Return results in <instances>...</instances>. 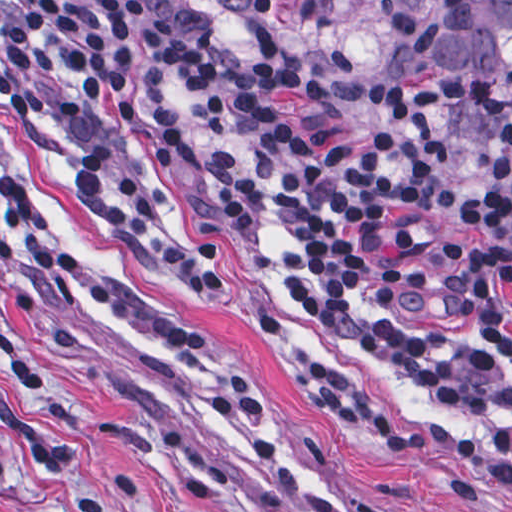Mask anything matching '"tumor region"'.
<instances>
[{"label":"tumor region","mask_w":512,"mask_h":512,"mask_svg":"<svg viewBox=\"0 0 512 512\" xmlns=\"http://www.w3.org/2000/svg\"><path fill=\"white\" fill-rule=\"evenodd\" d=\"M137 1L352 128L388 89L441 87L463 128L512 143V0Z\"/></svg>","instance_id":"obj_1"}]
</instances>
